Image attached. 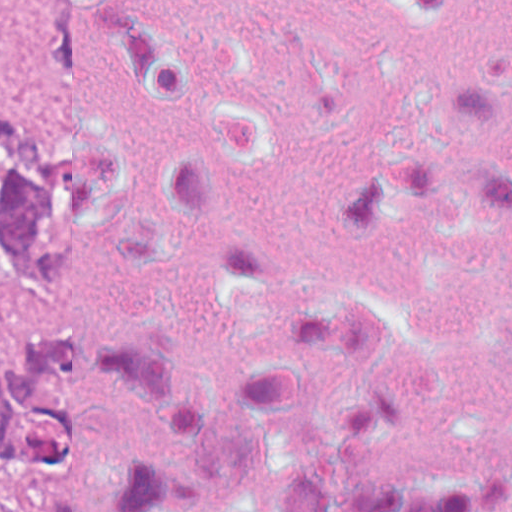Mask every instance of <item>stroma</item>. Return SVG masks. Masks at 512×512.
<instances>
[{
    "mask_svg": "<svg viewBox=\"0 0 512 512\" xmlns=\"http://www.w3.org/2000/svg\"><path fill=\"white\" fill-rule=\"evenodd\" d=\"M23 29V50L0 64V108L56 119V0H0V26ZM45 507V468H18L13 512Z\"/></svg>",
    "mask_w": 512,
    "mask_h": 512,
    "instance_id": "stroma-1",
    "label": "stroma"
}]
</instances>
